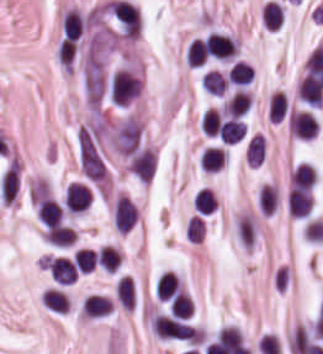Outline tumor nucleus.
I'll use <instances>...</instances> for the list:
<instances>
[{
    "label": "tumor nucleus",
    "instance_id": "2f306a5c",
    "mask_svg": "<svg viewBox=\"0 0 323 354\" xmlns=\"http://www.w3.org/2000/svg\"><path fill=\"white\" fill-rule=\"evenodd\" d=\"M126 162L142 182H150L156 166V157L149 148L140 144L128 155Z\"/></svg>",
    "mask_w": 323,
    "mask_h": 354
}]
</instances>
